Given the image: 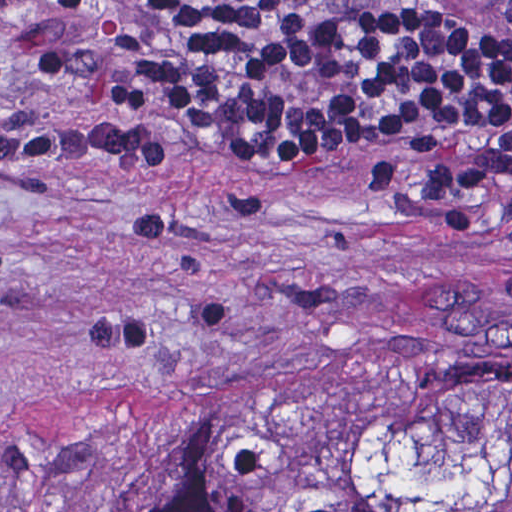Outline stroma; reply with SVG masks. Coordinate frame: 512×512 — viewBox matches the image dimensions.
<instances>
[{"instance_id":"1","label":"stroma","mask_w":512,"mask_h":512,"mask_svg":"<svg viewBox=\"0 0 512 512\" xmlns=\"http://www.w3.org/2000/svg\"><path fill=\"white\" fill-rule=\"evenodd\" d=\"M0 0V512H86L124 448L439 358L512 363V194L421 202L385 147L273 176L168 116L167 163L55 125L78 81Z\"/></svg>"}]
</instances>
